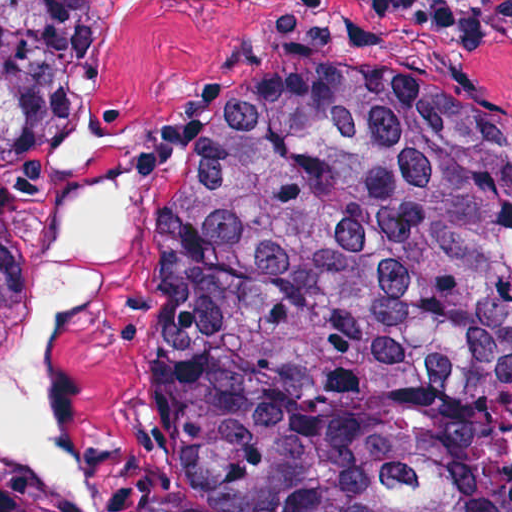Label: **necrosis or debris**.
Segmentation results:
<instances>
[{
  "label": "necrosis or debris",
  "mask_w": 512,
  "mask_h": 512,
  "mask_svg": "<svg viewBox=\"0 0 512 512\" xmlns=\"http://www.w3.org/2000/svg\"><path fill=\"white\" fill-rule=\"evenodd\" d=\"M470 512H512V381L496 396V472Z\"/></svg>",
  "instance_id": "necrosis-or-debris-1"
}]
</instances>
